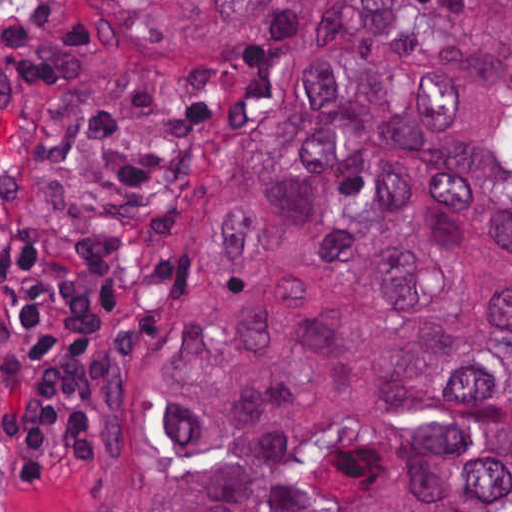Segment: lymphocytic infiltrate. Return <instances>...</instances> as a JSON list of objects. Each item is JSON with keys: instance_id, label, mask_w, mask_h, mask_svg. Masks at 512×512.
<instances>
[{"instance_id": "lymphocytic-infiltrate-1", "label": "lymphocytic infiltrate", "mask_w": 512, "mask_h": 512, "mask_svg": "<svg viewBox=\"0 0 512 512\" xmlns=\"http://www.w3.org/2000/svg\"><path fill=\"white\" fill-rule=\"evenodd\" d=\"M108 52L84 1H0V72L39 89L103 76ZM152 246L134 234L36 235L10 247V381L3 460L22 482L91 480L109 374Z\"/></svg>"}]
</instances>
